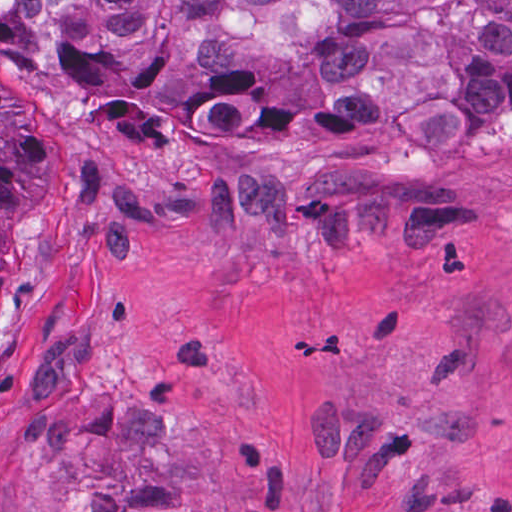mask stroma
Returning <instances> with one entry per match:
<instances>
[{
	"label": "stroma",
	"instance_id": "35a3bbf8",
	"mask_svg": "<svg viewBox=\"0 0 512 512\" xmlns=\"http://www.w3.org/2000/svg\"><path fill=\"white\" fill-rule=\"evenodd\" d=\"M0 68V512H512V109L231 168Z\"/></svg>",
	"mask_w": 512,
	"mask_h": 512
}]
</instances>
